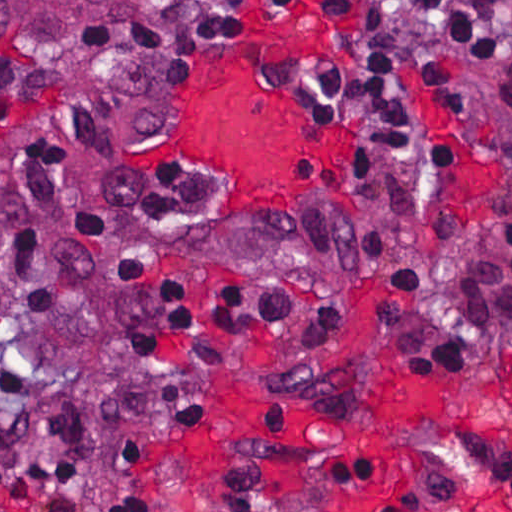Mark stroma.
Returning <instances> with one entry per match:
<instances>
[{"label":"stroma","instance_id":"35a3bbf8","mask_svg":"<svg viewBox=\"0 0 512 512\" xmlns=\"http://www.w3.org/2000/svg\"><path fill=\"white\" fill-rule=\"evenodd\" d=\"M217 1L172 0L98 69L57 66L0 49V193L9 187L11 163L25 140L49 138L68 152L80 187L72 204L53 210L50 230L70 227L80 210L98 212L107 231L96 246V274L113 268L129 246L139 244L153 255V268L133 284V312L149 308L156 284L166 277L178 281L193 304L190 324L161 338L137 373L129 332L106 290L77 288L58 316L21 323L10 314L2 320L0 360L25 368L36 383L25 390L40 398L33 435L0 447V461L57 458L50 422L59 406L96 421L86 441L85 487L45 491L75 501L76 512H115L132 494L147 499L154 512H330L316 502L244 505L197 490L183 476L185 451L230 427L236 388L258 377L293 401L344 420L356 435L432 481L422 444L400 435L389 415L387 391L409 388L445 403L479 469L501 499L512 501V102L423 0H399L400 28L436 46L461 77L476 132L409 72L427 177L393 172L369 179L358 132L329 123L306 83L282 84L270 70L279 57H318L344 67L351 51L342 32L358 9L328 11L326 0H297L288 9L243 3L241 14L254 28L250 38H225L210 54L201 48L183 79L166 80L154 62H141L139 75L160 96L164 116L153 128L139 129L113 84ZM302 18L318 20L329 34L267 48L249 71L246 89L295 99L315 139L343 149L345 162L317 184L306 209L287 213V220L270 206L230 203L220 173L180 158L190 115L220 66L272 27ZM106 95L107 117L117 132L114 148L86 140L65 115ZM172 165L201 182L205 206L168 233L144 217L154 179ZM403 278L428 284L432 312L458 326L464 364L456 372H415L405 366L394 335L381 328L384 285ZM244 280L272 282L307 302H345L354 326L336 338H305L267 325L218 333L220 291ZM175 380L205 398L208 419L184 421L154 409L145 395ZM21 407L19 399L0 392V417ZM112 430L146 455L143 464L122 463ZM0 512L35 511L0 495Z\"/></svg>","mask_w":512,"mask_h":512}]
</instances>
